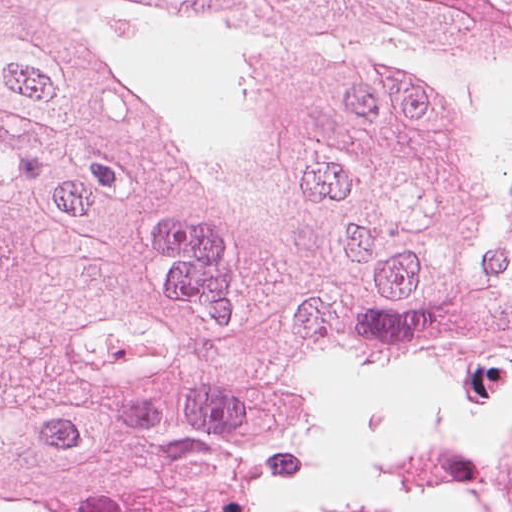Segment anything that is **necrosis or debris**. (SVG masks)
<instances>
[{
  "instance_id": "1",
  "label": "necrosis or debris",
  "mask_w": 512,
  "mask_h": 512,
  "mask_svg": "<svg viewBox=\"0 0 512 512\" xmlns=\"http://www.w3.org/2000/svg\"><path fill=\"white\" fill-rule=\"evenodd\" d=\"M306 512H456L445 501L410 495L332 506Z\"/></svg>"
}]
</instances>
